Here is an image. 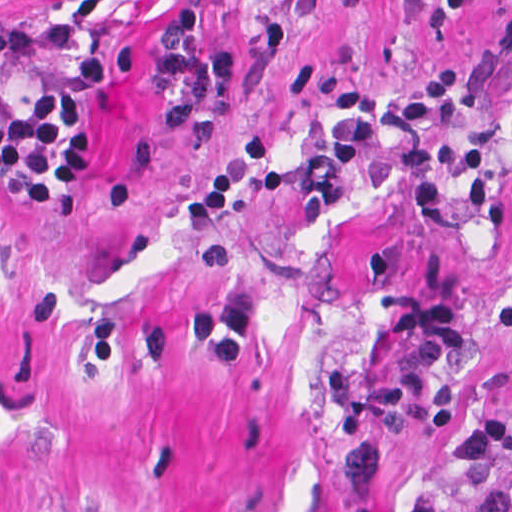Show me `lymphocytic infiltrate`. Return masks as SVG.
I'll use <instances>...</instances> for the list:
<instances>
[{
    "label": "lymphocytic infiltrate",
    "instance_id": "1",
    "mask_svg": "<svg viewBox=\"0 0 512 512\" xmlns=\"http://www.w3.org/2000/svg\"><path fill=\"white\" fill-rule=\"evenodd\" d=\"M204 18L197 5L178 7L147 40L96 49L74 63L71 76L100 92L127 80L140 56H149L156 62L151 85L162 99L164 126L183 132L231 97L237 82L234 56L202 45ZM77 84L50 80L19 100L0 80V188L31 213L72 209L90 182L86 115ZM455 89L456 73L447 66L427 72L400 98L353 80L326 83L322 94L346 129L319 151L315 163L283 162L270 139L247 137L186 199L185 216L219 217L236 205L249 178L264 194L328 205L341 196L383 133L391 132L397 141L401 208L412 231L443 234L457 227L440 169L466 216L484 230L503 228L506 207L487 180L500 127L487 120L477 124L470 140L447 147L434 143L441 109ZM490 331L506 369L508 394L463 425L450 465L439 476L440 512H512V293L493 311Z\"/></svg>",
    "mask_w": 512,
    "mask_h": 512
}]
</instances>
